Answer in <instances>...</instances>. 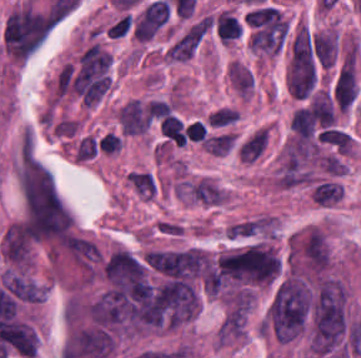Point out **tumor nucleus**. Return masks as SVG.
<instances>
[{"mask_svg":"<svg viewBox=\"0 0 361 358\" xmlns=\"http://www.w3.org/2000/svg\"><path fill=\"white\" fill-rule=\"evenodd\" d=\"M347 293L331 278L318 282L308 301L309 345L319 354L339 350L346 341Z\"/></svg>","mask_w":361,"mask_h":358,"instance_id":"tumor-nucleus-1","label":"tumor nucleus"},{"mask_svg":"<svg viewBox=\"0 0 361 358\" xmlns=\"http://www.w3.org/2000/svg\"><path fill=\"white\" fill-rule=\"evenodd\" d=\"M306 265L314 271H322L327 263L328 246L319 230H312L299 249Z\"/></svg>","mask_w":361,"mask_h":358,"instance_id":"tumor-nucleus-3","label":"tumor nucleus"},{"mask_svg":"<svg viewBox=\"0 0 361 358\" xmlns=\"http://www.w3.org/2000/svg\"><path fill=\"white\" fill-rule=\"evenodd\" d=\"M112 347V336L101 325H88L73 333V351L77 355L105 358Z\"/></svg>","mask_w":361,"mask_h":358,"instance_id":"tumor-nucleus-2","label":"tumor nucleus"}]
</instances>
